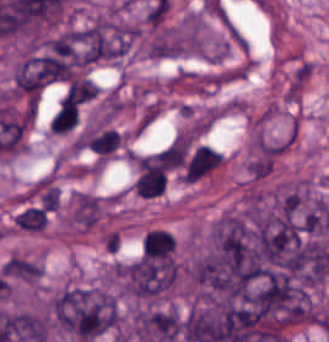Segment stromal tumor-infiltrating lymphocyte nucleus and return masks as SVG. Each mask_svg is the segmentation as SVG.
Segmentation results:
<instances>
[{"label": "stromal tumor-infiltrating lymphocyte nucleus", "instance_id": "6", "mask_svg": "<svg viewBox=\"0 0 329 342\" xmlns=\"http://www.w3.org/2000/svg\"><path fill=\"white\" fill-rule=\"evenodd\" d=\"M47 216L42 207H28L19 212L13 223L22 229L42 230L45 227Z\"/></svg>", "mask_w": 329, "mask_h": 342}, {"label": "stromal tumor-infiltrating lymphocyte nucleus", "instance_id": "4", "mask_svg": "<svg viewBox=\"0 0 329 342\" xmlns=\"http://www.w3.org/2000/svg\"><path fill=\"white\" fill-rule=\"evenodd\" d=\"M174 244L172 233L162 229H149L141 240V254L169 258Z\"/></svg>", "mask_w": 329, "mask_h": 342}, {"label": "stromal tumor-infiltrating lymphocyte nucleus", "instance_id": "2", "mask_svg": "<svg viewBox=\"0 0 329 342\" xmlns=\"http://www.w3.org/2000/svg\"><path fill=\"white\" fill-rule=\"evenodd\" d=\"M163 166L158 163H139L133 187L135 194L143 197L160 195L165 183Z\"/></svg>", "mask_w": 329, "mask_h": 342}, {"label": "stromal tumor-infiltrating lymphocyte nucleus", "instance_id": "1", "mask_svg": "<svg viewBox=\"0 0 329 342\" xmlns=\"http://www.w3.org/2000/svg\"><path fill=\"white\" fill-rule=\"evenodd\" d=\"M222 162L221 152L207 145H200L189 157L183 170L184 183H193Z\"/></svg>", "mask_w": 329, "mask_h": 342}, {"label": "stromal tumor-infiltrating lymphocyte nucleus", "instance_id": "5", "mask_svg": "<svg viewBox=\"0 0 329 342\" xmlns=\"http://www.w3.org/2000/svg\"><path fill=\"white\" fill-rule=\"evenodd\" d=\"M77 121V102L61 99L59 100L49 122V130L54 133H64Z\"/></svg>", "mask_w": 329, "mask_h": 342}, {"label": "stromal tumor-infiltrating lymphocyte nucleus", "instance_id": "3", "mask_svg": "<svg viewBox=\"0 0 329 342\" xmlns=\"http://www.w3.org/2000/svg\"><path fill=\"white\" fill-rule=\"evenodd\" d=\"M80 145L92 152L107 155L119 143V134L114 129H89L79 139Z\"/></svg>", "mask_w": 329, "mask_h": 342}]
</instances>
